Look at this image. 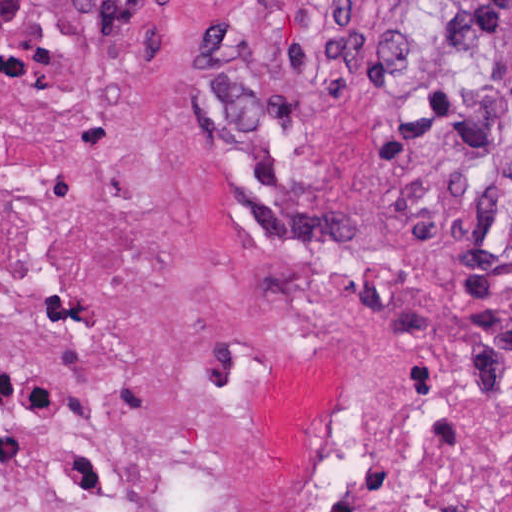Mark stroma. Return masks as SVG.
<instances>
[{"label":"stroma","instance_id":"stroma-1","mask_svg":"<svg viewBox=\"0 0 512 512\" xmlns=\"http://www.w3.org/2000/svg\"><path fill=\"white\" fill-rule=\"evenodd\" d=\"M431 0H0V122L105 112L143 151L181 141L204 92L249 68L351 42ZM478 124L458 158L469 169Z\"/></svg>","mask_w":512,"mask_h":512}]
</instances>
